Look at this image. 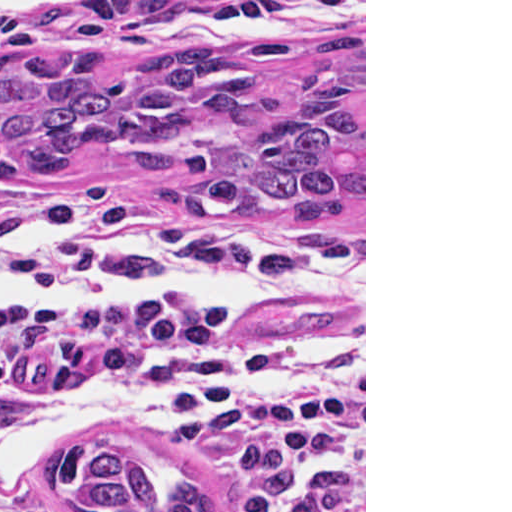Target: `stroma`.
Listing matches in <instances>:
<instances>
[{
	"label": "stroma",
	"mask_w": 512,
	"mask_h": 512,
	"mask_svg": "<svg viewBox=\"0 0 512 512\" xmlns=\"http://www.w3.org/2000/svg\"><path fill=\"white\" fill-rule=\"evenodd\" d=\"M347 34L364 35V210L322 231L198 224L177 213L166 188L92 155L71 158L46 182L0 184V236L7 228L76 222L28 258L37 273L66 289L83 284L96 258L136 233H148L172 252L201 254L220 233H233L276 247L323 249L365 265L362 293L279 297L238 307L257 338L365 335V376L318 384L333 398L325 449L274 512H366V0H0V62L109 51L118 58V78L166 54L210 47L250 55L262 77L283 83L309 73V59L325 37ZM165 363L158 347L83 333L32 363L2 417L7 424L45 395L70 387L136 385ZM82 433L183 454L216 500V463L199 427L188 420L161 427L145 417H106ZM31 497L42 506L79 512L48 475Z\"/></svg>",
	"instance_id": "stroma-1"
}]
</instances>
